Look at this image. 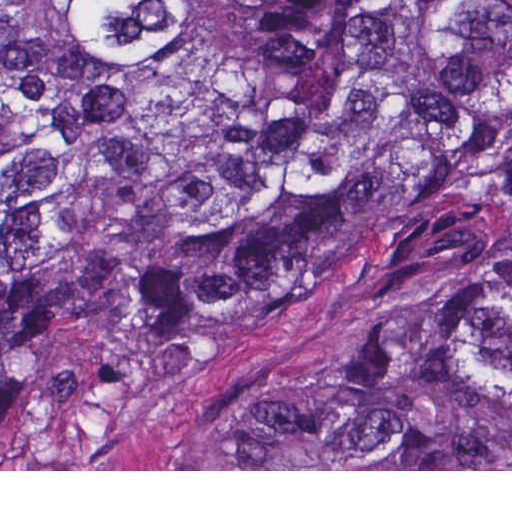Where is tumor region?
<instances>
[{"mask_svg": "<svg viewBox=\"0 0 512 512\" xmlns=\"http://www.w3.org/2000/svg\"><path fill=\"white\" fill-rule=\"evenodd\" d=\"M509 206L512 0H0V429ZM227 469H512V255L239 416Z\"/></svg>", "mask_w": 512, "mask_h": 512, "instance_id": "tumor-region-1", "label": "tumor region"}]
</instances>
